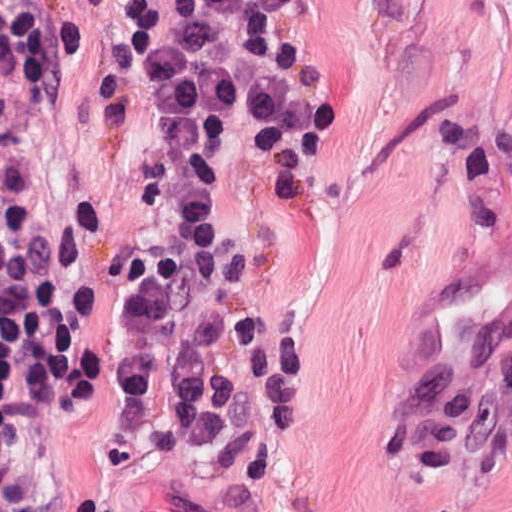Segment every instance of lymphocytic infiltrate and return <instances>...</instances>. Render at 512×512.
Here are the masks:
<instances>
[{
  "instance_id": "lymphocytic-infiltrate-1",
  "label": "lymphocytic infiltrate",
  "mask_w": 512,
  "mask_h": 512,
  "mask_svg": "<svg viewBox=\"0 0 512 512\" xmlns=\"http://www.w3.org/2000/svg\"><path fill=\"white\" fill-rule=\"evenodd\" d=\"M320 0H132L155 193L97 362L83 255L43 170L0 130V512H70L45 429L100 390L132 437L211 458L269 437L310 357L287 277L228 221L255 114L293 190L326 123Z\"/></svg>"
}]
</instances>
